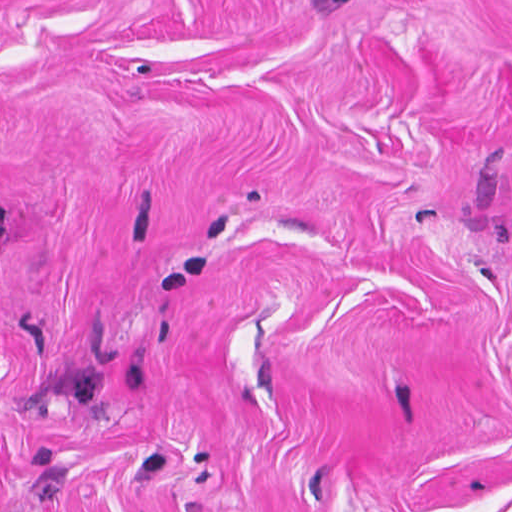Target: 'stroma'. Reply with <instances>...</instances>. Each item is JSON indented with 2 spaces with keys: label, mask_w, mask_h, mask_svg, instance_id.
Segmentation results:
<instances>
[{
  "label": "stroma",
  "mask_w": 512,
  "mask_h": 512,
  "mask_svg": "<svg viewBox=\"0 0 512 512\" xmlns=\"http://www.w3.org/2000/svg\"><path fill=\"white\" fill-rule=\"evenodd\" d=\"M0 512H512V0H0Z\"/></svg>",
  "instance_id": "1"
}]
</instances>
